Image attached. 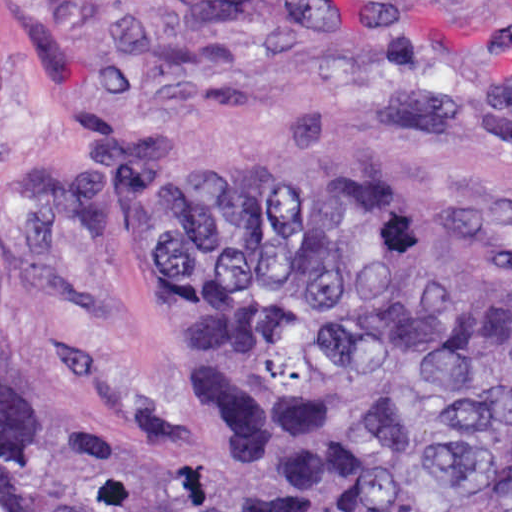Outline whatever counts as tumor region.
Segmentation results:
<instances>
[{"label":"tumor region","mask_w":512,"mask_h":512,"mask_svg":"<svg viewBox=\"0 0 512 512\" xmlns=\"http://www.w3.org/2000/svg\"><path fill=\"white\" fill-rule=\"evenodd\" d=\"M23 221L131 284L174 424L104 452L0 361V512H512V246L243 176L206 113L98 126Z\"/></svg>","instance_id":"1"}]
</instances>
